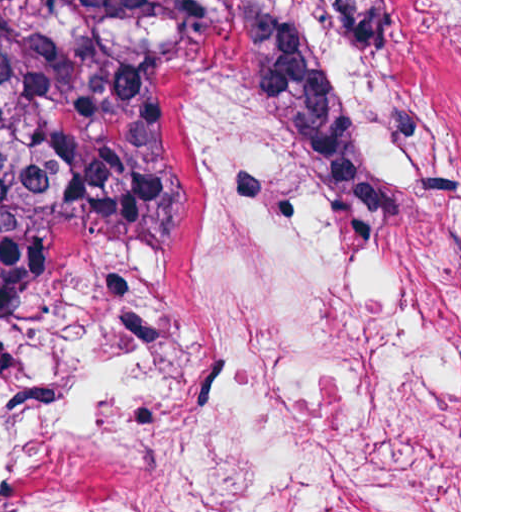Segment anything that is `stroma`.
Wrapping results in <instances>:
<instances>
[{
    "label": "stroma",
    "mask_w": 512,
    "mask_h": 512,
    "mask_svg": "<svg viewBox=\"0 0 512 512\" xmlns=\"http://www.w3.org/2000/svg\"><path fill=\"white\" fill-rule=\"evenodd\" d=\"M455 166L353 235L242 43L170 169L171 248L49 240L0 322V512H461V0H395Z\"/></svg>",
    "instance_id": "1"
}]
</instances>
